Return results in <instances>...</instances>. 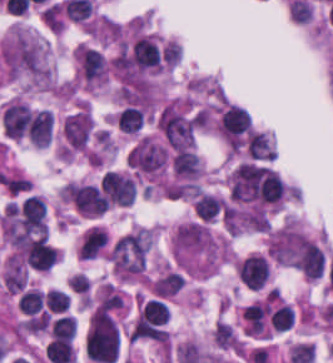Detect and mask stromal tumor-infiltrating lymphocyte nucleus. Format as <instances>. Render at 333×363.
Here are the masks:
<instances>
[{
    "label": "stromal tumor-infiltrating lymphocyte nucleus",
    "mask_w": 333,
    "mask_h": 363,
    "mask_svg": "<svg viewBox=\"0 0 333 363\" xmlns=\"http://www.w3.org/2000/svg\"><path fill=\"white\" fill-rule=\"evenodd\" d=\"M31 113L22 102L11 101L2 109L1 125L5 135L20 138L26 129Z\"/></svg>",
    "instance_id": "3"
},
{
    "label": "stromal tumor-infiltrating lymphocyte nucleus",
    "mask_w": 333,
    "mask_h": 363,
    "mask_svg": "<svg viewBox=\"0 0 333 363\" xmlns=\"http://www.w3.org/2000/svg\"><path fill=\"white\" fill-rule=\"evenodd\" d=\"M235 274L243 286L249 290L265 288L268 282L269 262L264 253L252 252L239 258Z\"/></svg>",
    "instance_id": "1"
},
{
    "label": "stromal tumor-infiltrating lymphocyte nucleus",
    "mask_w": 333,
    "mask_h": 363,
    "mask_svg": "<svg viewBox=\"0 0 333 363\" xmlns=\"http://www.w3.org/2000/svg\"><path fill=\"white\" fill-rule=\"evenodd\" d=\"M92 136V118L85 109L68 114L63 124L65 149L82 150L87 147Z\"/></svg>",
    "instance_id": "2"
},
{
    "label": "stromal tumor-infiltrating lymphocyte nucleus",
    "mask_w": 333,
    "mask_h": 363,
    "mask_svg": "<svg viewBox=\"0 0 333 363\" xmlns=\"http://www.w3.org/2000/svg\"><path fill=\"white\" fill-rule=\"evenodd\" d=\"M45 299L49 311H64L69 301L65 290L51 287L45 290Z\"/></svg>",
    "instance_id": "5"
},
{
    "label": "stromal tumor-infiltrating lymphocyte nucleus",
    "mask_w": 333,
    "mask_h": 363,
    "mask_svg": "<svg viewBox=\"0 0 333 363\" xmlns=\"http://www.w3.org/2000/svg\"><path fill=\"white\" fill-rule=\"evenodd\" d=\"M51 118L46 108L34 111L28 121L26 135L31 144L45 145L50 140Z\"/></svg>",
    "instance_id": "4"
}]
</instances>
